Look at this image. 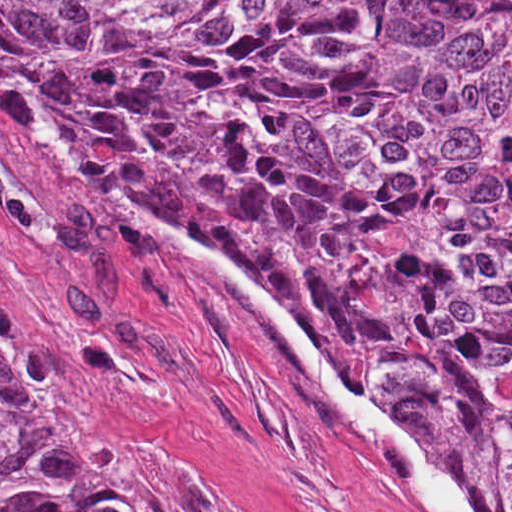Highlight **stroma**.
<instances>
[{
  "label": "stroma",
  "mask_w": 512,
  "mask_h": 512,
  "mask_svg": "<svg viewBox=\"0 0 512 512\" xmlns=\"http://www.w3.org/2000/svg\"><path fill=\"white\" fill-rule=\"evenodd\" d=\"M172 232L209 247L85 170L43 96L0 71V320L30 407L158 512H429L257 302L164 248Z\"/></svg>",
  "instance_id": "35a3bbf8"
}]
</instances>
